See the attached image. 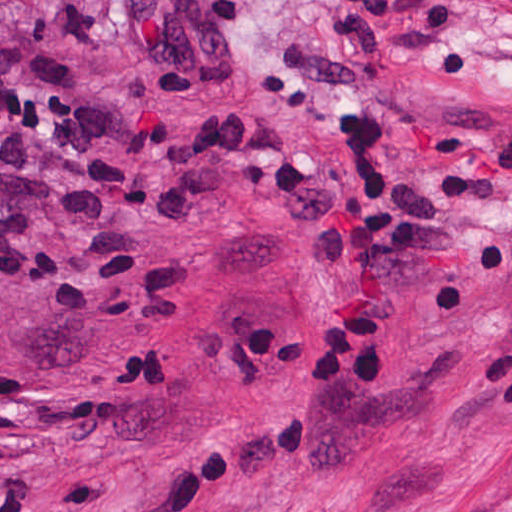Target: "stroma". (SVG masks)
<instances>
[{
    "instance_id": "obj_1",
    "label": "stroma",
    "mask_w": 512,
    "mask_h": 512,
    "mask_svg": "<svg viewBox=\"0 0 512 512\" xmlns=\"http://www.w3.org/2000/svg\"><path fill=\"white\" fill-rule=\"evenodd\" d=\"M124 0H0V512H512V0L449 43L478 75L377 68L406 174L453 236L408 258L391 381L317 385L333 248L180 167L232 122L349 172L262 104L324 0H246L241 75L167 96Z\"/></svg>"
}]
</instances>
